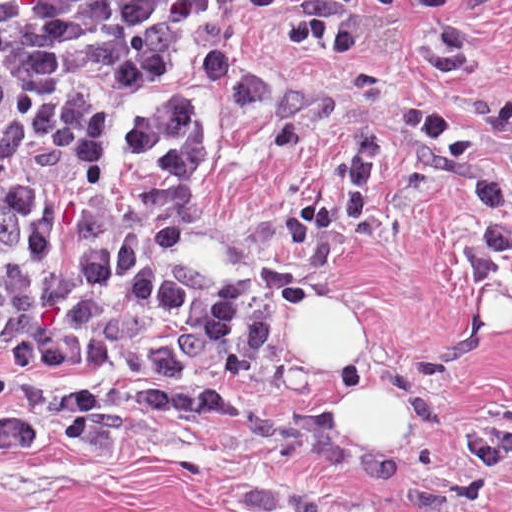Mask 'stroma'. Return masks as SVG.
Here are the masks:
<instances>
[{
  "instance_id": "obj_1",
  "label": "stroma",
  "mask_w": 512,
  "mask_h": 512,
  "mask_svg": "<svg viewBox=\"0 0 512 512\" xmlns=\"http://www.w3.org/2000/svg\"><path fill=\"white\" fill-rule=\"evenodd\" d=\"M232 1L216 40L330 89L333 111L277 147L259 117L200 89L207 165L175 202L188 250L251 295V350L225 385L164 369H0V512H512V463L483 505L432 487L464 434L512 410V259L470 280L478 201L447 153L395 124L453 120L512 194V0H367L345 57L277 44L292 0ZM378 142L360 232L311 302L259 262L324 197L359 133Z\"/></svg>"
}]
</instances>
